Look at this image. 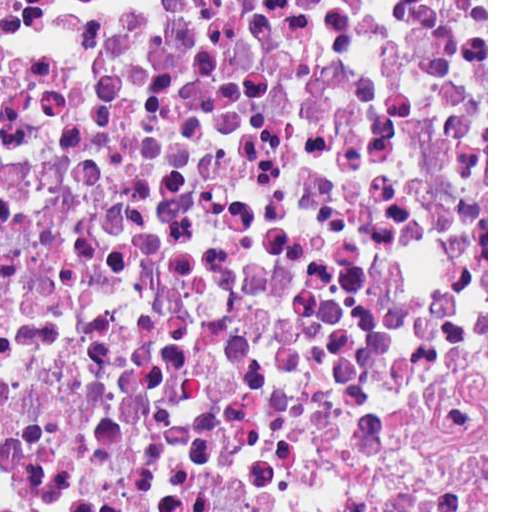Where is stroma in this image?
<instances>
[{
  "mask_svg": "<svg viewBox=\"0 0 512 512\" xmlns=\"http://www.w3.org/2000/svg\"><path fill=\"white\" fill-rule=\"evenodd\" d=\"M0 1H271V0H0ZM486 512H488V0H487V405H486Z\"/></svg>",
  "mask_w": 512,
  "mask_h": 512,
  "instance_id": "1",
  "label": "stroma"
}]
</instances>
